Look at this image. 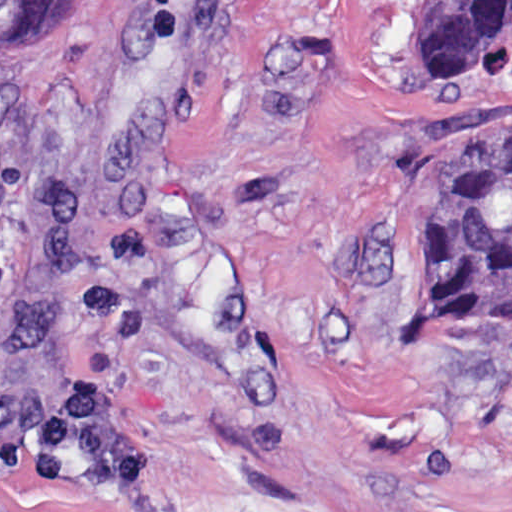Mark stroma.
<instances>
[{"label":"stroma","mask_w":512,"mask_h":512,"mask_svg":"<svg viewBox=\"0 0 512 512\" xmlns=\"http://www.w3.org/2000/svg\"><path fill=\"white\" fill-rule=\"evenodd\" d=\"M423 0H66L0 62V440L83 381L142 462L0 512H512V326L406 328V245L512 120Z\"/></svg>","instance_id":"obj_1"}]
</instances>
